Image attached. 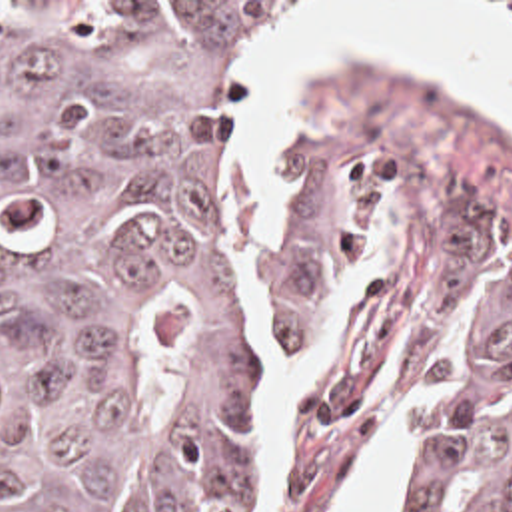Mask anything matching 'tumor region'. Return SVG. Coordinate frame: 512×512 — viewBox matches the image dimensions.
Returning <instances> with one entry per match:
<instances>
[{"label": "tumor region", "instance_id": "obj_1", "mask_svg": "<svg viewBox=\"0 0 512 512\" xmlns=\"http://www.w3.org/2000/svg\"><path fill=\"white\" fill-rule=\"evenodd\" d=\"M297 22L0 2V512L273 505L239 146ZM453 266L451 391L405 512H512V258L457 236Z\"/></svg>", "mask_w": 512, "mask_h": 512}]
</instances>
